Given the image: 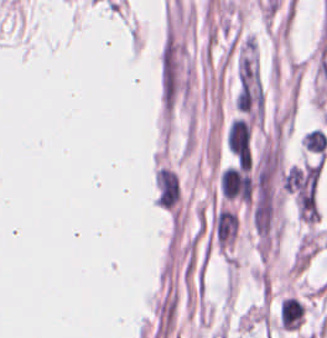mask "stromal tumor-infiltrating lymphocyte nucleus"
I'll return each mask as SVG.
<instances>
[{"instance_id": "bc302bb0", "label": "stromal tumor-infiltrating lymphocyte nucleus", "mask_w": 327, "mask_h": 338, "mask_svg": "<svg viewBox=\"0 0 327 338\" xmlns=\"http://www.w3.org/2000/svg\"><path fill=\"white\" fill-rule=\"evenodd\" d=\"M305 308L296 297H283L279 306L280 326L285 330H297Z\"/></svg>"}, {"instance_id": "52c7bb5b", "label": "stromal tumor-infiltrating lymphocyte nucleus", "mask_w": 327, "mask_h": 338, "mask_svg": "<svg viewBox=\"0 0 327 338\" xmlns=\"http://www.w3.org/2000/svg\"><path fill=\"white\" fill-rule=\"evenodd\" d=\"M300 141L304 149L323 155L327 144L326 133L314 127L310 130L305 131Z\"/></svg>"}]
</instances>
